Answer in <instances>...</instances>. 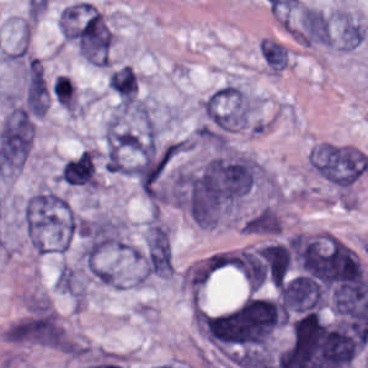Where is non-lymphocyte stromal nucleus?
<instances>
[{"label":"non-lymphocyte stromal nucleus","mask_w":368,"mask_h":368,"mask_svg":"<svg viewBox=\"0 0 368 368\" xmlns=\"http://www.w3.org/2000/svg\"><path fill=\"white\" fill-rule=\"evenodd\" d=\"M311 165L328 181L338 186H349L366 170L368 158L358 147L321 142L311 151Z\"/></svg>","instance_id":"non-lymphocyte-stromal-nucleus-3"},{"label":"non-lymphocyte stromal nucleus","mask_w":368,"mask_h":368,"mask_svg":"<svg viewBox=\"0 0 368 368\" xmlns=\"http://www.w3.org/2000/svg\"><path fill=\"white\" fill-rule=\"evenodd\" d=\"M163 227L157 221H149L147 225L146 233V246H145V259H144V272L143 279L146 275L153 253L157 246Z\"/></svg>","instance_id":"non-lymphocyte-stromal-nucleus-12"},{"label":"non-lymphocyte stromal nucleus","mask_w":368,"mask_h":368,"mask_svg":"<svg viewBox=\"0 0 368 368\" xmlns=\"http://www.w3.org/2000/svg\"><path fill=\"white\" fill-rule=\"evenodd\" d=\"M228 256L229 252L214 249L185 266L180 285L188 301L201 304L223 270Z\"/></svg>","instance_id":"non-lymphocyte-stromal-nucleus-5"},{"label":"non-lymphocyte stromal nucleus","mask_w":368,"mask_h":368,"mask_svg":"<svg viewBox=\"0 0 368 368\" xmlns=\"http://www.w3.org/2000/svg\"><path fill=\"white\" fill-rule=\"evenodd\" d=\"M52 92L59 105L69 111H74L76 104L75 86L71 78L57 74Z\"/></svg>","instance_id":"non-lymphocyte-stromal-nucleus-11"},{"label":"non-lymphocyte stromal nucleus","mask_w":368,"mask_h":368,"mask_svg":"<svg viewBox=\"0 0 368 368\" xmlns=\"http://www.w3.org/2000/svg\"><path fill=\"white\" fill-rule=\"evenodd\" d=\"M253 184L249 157L220 154L178 173L175 201L199 227H216Z\"/></svg>","instance_id":"non-lymphocyte-stromal-nucleus-1"},{"label":"non-lymphocyte stromal nucleus","mask_w":368,"mask_h":368,"mask_svg":"<svg viewBox=\"0 0 368 368\" xmlns=\"http://www.w3.org/2000/svg\"><path fill=\"white\" fill-rule=\"evenodd\" d=\"M206 129L226 132L252 122L249 93L241 86L226 83L205 99Z\"/></svg>","instance_id":"non-lymphocyte-stromal-nucleus-4"},{"label":"non-lymphocyte stromal nucleus","mask_w":368,"mask_h":368,"mask_svg":"<svg viewBox=\"0 0 368 368\" xmlns=\"http://www.w3.org/2000/svg\"><path fill=\"white\" fill-rule=\"evenodd\" d=\"M107 86L121 99L133 101L136 96L137 77L131 66L122 65L107 79Z\"/></svg>","instance_id":"non-lymphocyte-stromal-nucleus-7"},{"label":"non-lymphocyte stromal nucleus","mask_w":368,"mask_h":368,"mask_svg":"<svg viewBox=\"0 0 368 368\" xmlns=\"http://www.w3.org/2000/svg\"><path fill=\"white\" fill-rule=\"evenodd\" d=\"M259 52L270 69L280 71L287 67L286 48L282 43L264 37L259 41Z\"/></svg>","instance_id":"non-lymphocyte-stromal-nucleus-9"},{"label":"non-lymphocyte stromal nucleus","mask_w":368,"mask_h":368,"mask_svg":"<svg viewBox=\"0 0 368 368\" xmlns=\"http://www.w3.org/2000/svg\"><path fill=\"white\" fill-rule=\"evenodd\" d=\"M64 185L83 189H95L99 183L95 153L83 150L67 159L60 169Z\"/></svg>","instance_id":"non-lymphocyte-stromal-nucleus-6"},{"label":"non-lymphocyte stromal nucleus","mask_w":368,"mask_h":368,"mask_svg":"<svg viewBox=\"0 0 368 368\" xmlns=\"http://www.w3.org/2000/svg\"><path fill=\"white\" fill-rule=\"evenodd\" d=\"M57 289L63 294H83L84 282L78 271L69 265H62L56 276Z\"/></svg>","instance_id":"non-lymphocyte-stromal-nucleus-10"},{"label":"non-lymphocyte stromal nucleus","mask_w":368,"mask_h":368,"mask_svg":"<svg viewBox=\"0 0 368 368\" xmlns=\"http://www.w3.org/2000/svg\"><path fill=\"white\" fill-rule=\"evenodd\" d=\"M281 216L270 206H263L243 221L242 231L246 233L280 231Z\"/></svg>","instance_id":"non-lymphocyte-stromal-nucleus-8"},{"label":"non-lymphocyte stromal nucleus","mask_w":368,"mask_h":368,"mask_svg":"<svg viewBox=\"0 0 368 368\" xmlns=\"http://www.w3.org/2000/svg\"><path fill=\"white\" fill-rule=\"evenodd\" d=\"M26 235L38 253H64L75 229V215L68 200L53 189H43L24 205Z\"/></svg>","instance_id":"non-lymphocyte-stromal-nucleus-2"}]
</instances>
